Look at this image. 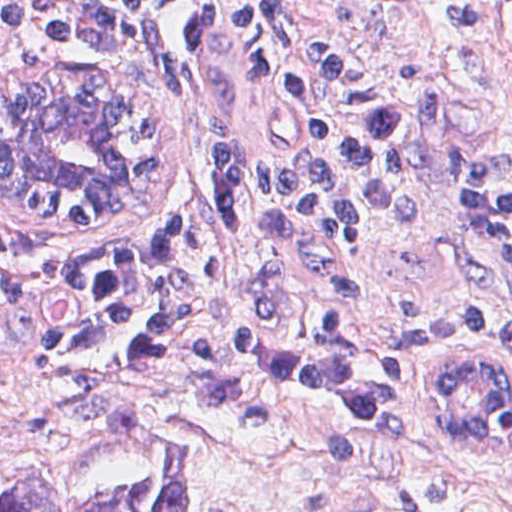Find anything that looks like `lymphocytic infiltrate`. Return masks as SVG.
Masks as SVG:
<instances>
[{
    "mask_svg": "<svg viewBox=\"0 0 512 512\" xmlns=\"http://www.w3.org/2000/svg\"><path fill=\"white\" fill-rule=\"evenodd\" d=\"M208 1L0 0V33L99 71L184 32ZM233 10L264 79L278 147L265 161L215 168L181 231L0 259V319L14 347L36 361L150 386L239 428L289 438L278 433L372 425L402 404L387 376L220 323L216 229L339 249L357 236L367 200L400 175L402 118L341 62L303 0H233ZM448 155L471 243L511 256L505 163L485 141L453 143ZM488 345L512 363L511 310L469 306L416 321L394 347L395 360L420 373L429 438L456 459L512 450V397L482 447L464 446L426 410L423 365Z\"/></svg>",
    "mask_w": 512,
    "mask_h": 512,
    "instance_id": "obj_1",
    "label": "lymphocytic infiltrate"
}]
</instances>
